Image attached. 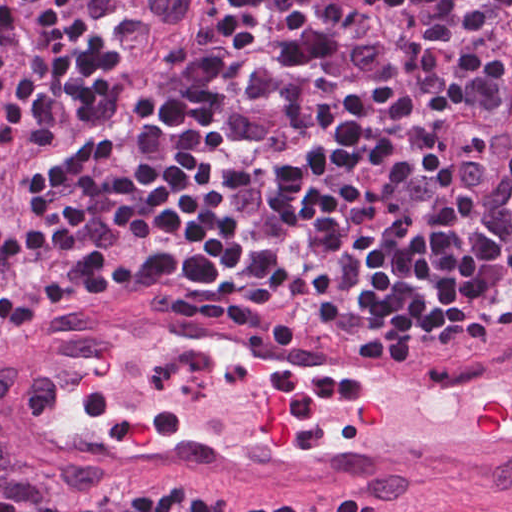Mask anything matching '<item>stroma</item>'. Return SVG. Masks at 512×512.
Listing matches in <instances>:
<instances>
[{
	"mask_svg": "<svg viewBox=\"0 0 512 512\" xmlns=\"http://www.w3.org/2000/svg\"><path fill=\"white\" fill-rule=\"evenodd\" d=\"M119 294L149 299L193 318L244 327L321 328L311 317L302 315H250L240 309H206L163 286H112L56 311L30 313L0 324V392L8 371L43 330L99 299ZM134 484H155L167 491H192L267 510L512 512V491H469L350 474L267 476L222 483L65 475L39 459L18 439L0 395V492L23 499L39 512H61L95 494Z\"/></svg>",
	"mask_w": 512,
	"mask_h": 512,
	"instance_id": "stroma-1",
	"label": "stroma"
}]
</instances>
